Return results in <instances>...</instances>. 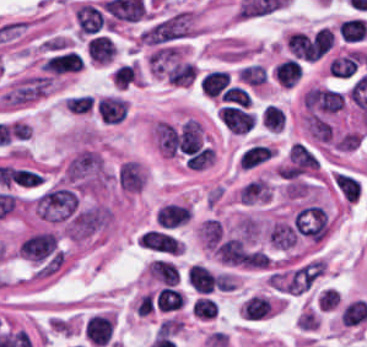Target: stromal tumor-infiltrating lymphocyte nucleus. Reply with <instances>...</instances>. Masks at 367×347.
I'll use <instances>...</instances> for the list:
<instances>
[{
	"mask_svg": "<svg viewBox=\"0 0 367 347\" xmlns=\"http://www.w3.org/2000/svg\"><path fill=\"white\" fill-rule=\"evenodd\" d=\"M141 71L137 63H123L112 68L110 79L117 88H128L141 79Z\"/></svg>",
	"mask_w": 367,
	"mask_h": 347,
	"instance_id": "3",
	"label": "stromal tumor-infiltrating lymphocyte nucleus"
},
{
	"mask_svg": "<svg viewBox=\"0 0 367 347\" xmlns=\"http://www.w3.org/2000/svg\"><path fill=\"white\" fill-rule=\"evenodd\" d=\"M338 31L343 40L361 41L367 32V25L363 18H349L339 23Z\"/></svg>",
	"mask_w": 367,
	"mask_h": 347,
	"instance_id": "6",
	"label": "stromal tumor-infiltrating lymphocyte nucleus"
},
{
	"mask_svg": "<svg viewBox=\"0 0 367 347\" xmlns=\"http://www.w3.org/2000/svg\"><path fill=\"white\" fill-rule=\"evenodd\" d=\"M191 207L187 204L170 202L159 207L154 222L161 230H175L187 223Z\"/></svg>",
	"mask_w": 367,
	"mask_h": 347,
	"instance_id": "1",
	"label": "stromal tumor-infiltrating lymphocyte nucleus"
},
{
	"mask_svg": "<svg viewBox=\"0 0 367 347\" xmlns=\"http://www.w3.org/2000/svg\"><path fill=\"white\" fill-rule=\"evenodd\" d=\"M285 119L284 112L277 106L265 104L258 112L257 121L267 131H280Z\"/></svg>",
	"mask_w": 367,
	"mask_h": 347,
	"instance_id": "5",
	"label": "stromal tumor-infiltrating lymphocyte nucleus"
},
{
	"mask_svg": "<svg viewBox=\"0 0 367 347\" xmlns=\"http://www.w3.org/2000/svg\"><path fill=\"white\" fill-rule=\"evenodd\" d=\"M301 73L300 66L296 61L284 60L276 64L272 75L276 82L283 88H291Z\"/></svg>",
	"mask_w": 367,
	"mask_h": 347,
	"instance_id": "4",
	"label": "stromal tumor-infiltrating lymphocyte nucleus"
},
{
	"mask_svg": "<svg viewBox=\"0 0 367 347\" xmlns=\"http://www.w3.org/2000/svg\"><path fill=\"white\" fill-rule=\"evenodd\" d=\"M138 245L168 255H181L182 244L169 234L155 230L145 231Z\"/></svg>",
	"mask_w": 367,
	"mask_h": 347,
	"instance_id": "2",
	"label": "stromal tumor-infiltrating lymphocyte nucleus"
}]
</instances>
